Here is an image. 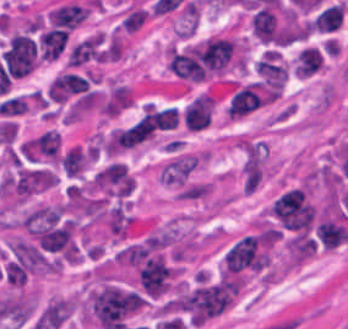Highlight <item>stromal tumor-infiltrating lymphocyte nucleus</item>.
I'll return each instance as SVG.
<instances>
[{
  "mask_svg": "<svg viewBox=\"0 0 348 329\" xmlns=\"http://www.w3.org/2000/svg\"><path fill=\"white\" fill-rule=\"evenodd\" d=\"M327 61V52L321 46L305 43L295 52L291 61L294 76L310 78L323 70Z\"/></svg>",
  "mask_w": 348,
  "mask_h": 329,
  "instance_id": "5",
  "label": "stromal tumor-infiltrating lymphocyte nucleus"
},
{
  "mask_svg": "<svg viewBox=\"0 0 348 329\" xmlns=\"http://www.w3.org/2000/svg\"><path fill=\"white\" fill-rule=\"evenodd\" d=\"M67 40L65 30L46 28L43 46L45 61L50 63L58 58Z\"/></svg>",
  "mask_w": 348,
  "mask_h": 329,
  "instance_id": "12",
  "label": "stromal tumor-infiltrating lymphocyte nucleus"
},
{
  "mask_svg": "<svg viewBox=\"0 0 348 329\" xmlns=\"http://www.w3.org/2000/svg\"><path fill=\"white\" fill-rule=\"evenodd\" d=\"M89 12L87 6L67 1L49 10L47 17L52 26L72 28Z\"/></svg>",
  "mask_w": 348,
  "mask_h": 329,
  "instance_id": "9",
  "label": "stromal tumor-infiltrating lymphocyte nucleus"
},
{
  "mask_svg": "<svg viewBox=\"0 0 348 329\" xmlns=\"http://www.w3.org/2000/svg\"><path fill=\"white\" fill-rule=\"evenodd\" d=\"M251 33L260 41L280 43L274 7L262 6L254 12L250 20Z\"/></svg>",
  "mask_w": 348,
  "mask_h": 329,
  "instance_id": "8",
  "label": "stromal tumor-infiltrating lymphocyte nucleus"
},
{
  "mask_svg": "<svg viewBox=\"0 0 348 329\" xmlns=\"http://www.w3.org/2000/svg\"><path fill=\"white\" fill-rule=\"evenodd\" d=\"M82 86V77L74 71H61L47 86V97L56 101H65Z\"/></svg>",
  "mask_w": 348,
  "mask_h": 329,
  "instance_id": "10",
  "label": "stromal tumor-infiltrating lymphocyte nucleus"
},
{
  "mask_svg": "<svg viewBox=\"0 0 348 329\" xmlns=\"http://www.w3.org/2000/svg\"><path fill=\"white\" fill-rule=\"evenodd\" d=\"M105 58H107L105 33L96 31L72 45L65 58V64L77 66Z\"/></svg>",
  "mask_w": 348,
  "mask_h": 329,
  "instance_id": "4",
  "label": "stromal tumor-infiltrating lymphocyte nucleus"
},
{
  "mask_svg": "<svg viewBox=\"0 0 348 329\" xmlns=\"http://www.w3.org/2000/svg\"><path fill=\"white\" fill-rule=\"evenodd\" d=\"M0 58L11 76H25L37 65L35 39L28 32L15 31L9 36Z\"/></svg>",
  "mask_w": 348,
  "mask_h": 329,
  "instance_id": "1",
  "label": "stromal tumor-infiltrating lymphocyte nucleus"
},
{
  "mask_svg": "<svg viewBox=\"0 0 348 329\" xmlns=\"http://www.w3.org/2000/svg\"><path fill=\"white\" fill-rule=\"evenodd\" d=\"M62 138L55 128H48L29 140V156L34 160L57 162L60 158Z\"/></svg>",
  "mask_w": 348,
  "mask_h": 329,
  "instance_id": "7",
  "label": "stromal tumor-infiltrating lymphocyte nucleus"
},
{
  "mask_svg": "<svg viewBox=\"0 0 348 329\" xmlns=\"http://www.w3.org/2000/svg\"><path fill=\"white\" fill-rule=\"evenodd\" d=\"M135 178L123 162L111 161L91 178L90 189L108 198H123L134 189Z\"/></svg>",
  "mask_w": 348,
  "mask_h": 329,
  "instance_id": "2",
  "label": "stromal tumor-infiltrating lymphocyte nucleus"
},
{
  "mask_svg": "<svg viewBox=\"0 0 348 329\" xmlns=\"http://www.w3.org/2000/svg\"><path fill=\"white\" fill-rule=\"evenodd\" d=\"M345 4L336 2L322 9L311 23V29L320 32H334L343 25Z\"/></svg>",
  "mask_w": 348,
  "mask_h": 329,
  "instance_id": "11",
  "label": "stromal tumor-infiltrating lymphocyte nucleus"
},
{
  "mask_svg": "<svg viewBox=\"0 0 348 329\" xmlns=\"http://www.w3.org/2000/svg\"><path fill=\"white\" fill-rule=\"evenodd\" d=\"M253 67L262 85L284 87L289 78V68L274 48L264 50Z\"/></svg>",
  "mask_w": 348,
  "mask_h": 329,
  "instance_id": "3",
  "label": "stromal tumor-infiltrating lymphocyte nucleus"
},
{
  "mask_svg": "<svg viewBox=\"0 0 348 329\" xmlns=\"http://www.w3.org/2000/svg\"><path fill=\"white\" fill-rule=\"evenodd\" d=\"M215 109L213 95L210 92H202L188 102L182 115L183 124L187 130H200L205 128Z\"/></svg>",
  "mask_w": 348,
  "mask_h": 329,
  "instance_id": "6",
  "label": "stromal tumor-infiltrating lymphocyte nucleus"
}]
</instances>
